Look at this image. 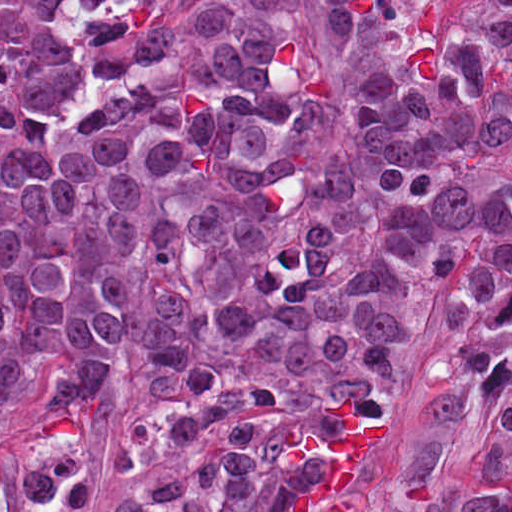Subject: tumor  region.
<instances>
[{
  "instance_id": "e687c5a6",
  "label": "tumor region",
  "mask_w": 512,
  "mask_h": 512,
  "mask_svg": "<svg viewBox=\"0 0 512 512\" xmlns=\"http://www.w3.org/2000/svg\"><path fill=\"white\" fill-rule=\"evenodd\" d=\"M442 353L377 494L390 406ZM134 354L110 512L297 511L341 387L377 442L346 512H512V0H0V418ZM493 427L476 494L438 476ZM77 437L0 458V512H87Z\"/></svg>"
}]
</instances>
